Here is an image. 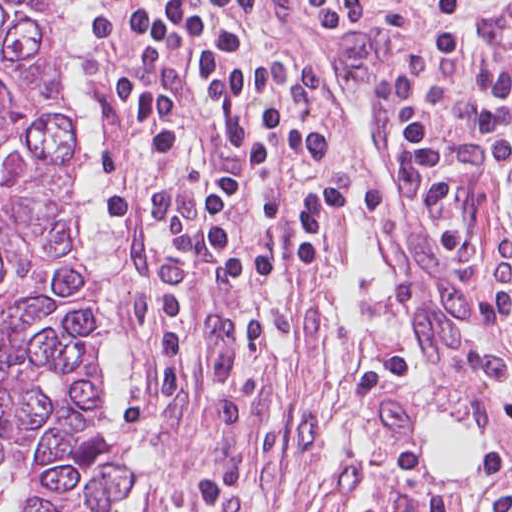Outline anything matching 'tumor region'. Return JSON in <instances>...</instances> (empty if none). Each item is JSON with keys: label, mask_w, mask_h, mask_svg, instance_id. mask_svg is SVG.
Here are the masks:
<instances>
[{"label": "tumor region", "mask_w": 512, "mask_h": 512, "mask_svg": "<svg viewBox=\"0 0 512 512\" xmlns=\"http://www.w3.org/2000/svg\"><path fill=\"white\" fill-rule=\"evenodd\" d=\"M78 249V109L51 0H0V477L24 512H127L106 319Z\"/></svg>", "instance_id": "obj_1"}]
</instances>
